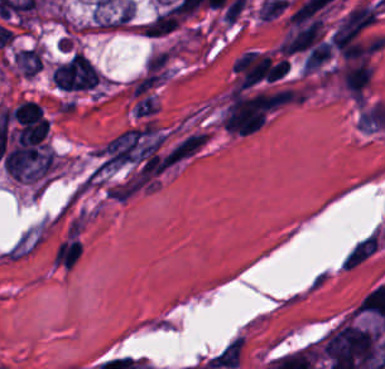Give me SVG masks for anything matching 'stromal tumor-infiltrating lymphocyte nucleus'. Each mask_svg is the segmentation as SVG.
Here are the masks:
<instances>
[{
  "mask_svg": "<svg viewBox=\"0 0 385 369\" xmlns=\"http://www.w3.org/2000/svg\"><path fill=\"white\" fill-rule=\"evenodd\" d=\"M10 114L13 120L21 124L41 115V107L31 99H24L14 107Z\"/></svg>",
  "mask_w": 385,
  "mask_h": 369,
  "instance_id": "obj_1",
  "label": "stromal tumor-infiltrating lymphocyte nucleus"
}]
</instances>
